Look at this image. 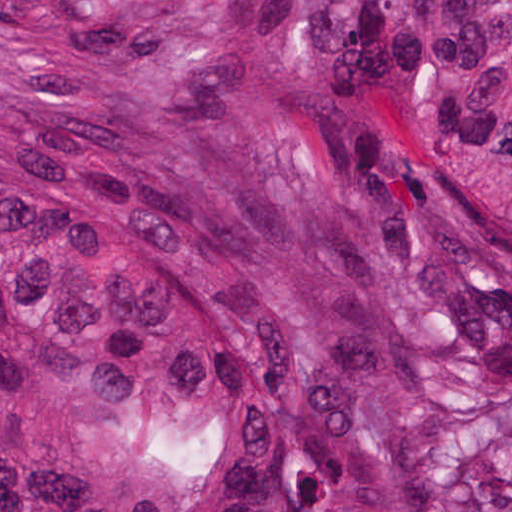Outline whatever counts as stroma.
<instances>
[{
	"instance_id": "obj_1",
	"label": "stroma",
	"mask_w": 512,
	"mask_h": 512,
	"mask_svg": "<svg viewBox=\"0 0 512 512\" xmlns=\"http://www.w3.org/2000/svg\"><path fill=\"white\" fill-rule=\"evenodd\" d=\"M421 512H512V287L431 231ZM1 512V0H0Z\"/></svg>"
}]
</instances>
